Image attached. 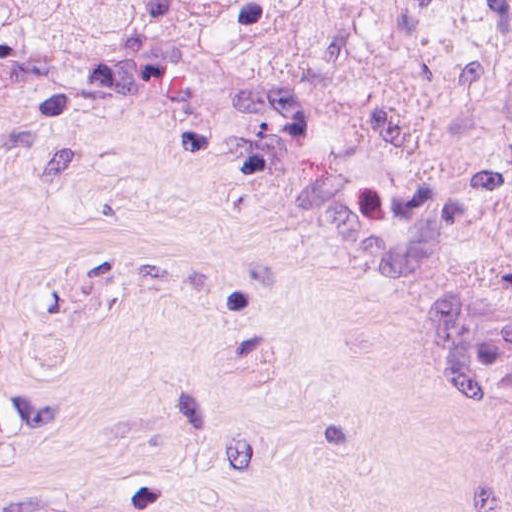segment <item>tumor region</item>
Wrapping results in <instances>:
<instances>
[{"instance_id": "obj_1", "label": "tumor region", "mask_w": 512, "mask_h": 512, "mask_svg": "<svg viewBox=\"0 0 512 512\" xmlns=\"http://www.w3.org/2000/svg\"><path fill=\"white\" fill-rule=\"evenodd\" d=\"M117 100L512 321V0H0V240Z\"/></svg>"}]
</instances>
